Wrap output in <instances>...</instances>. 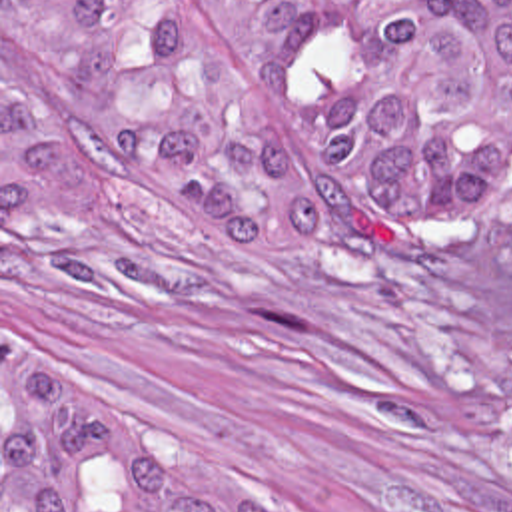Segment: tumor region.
Wrapping results in <instances>:
<instances>
[{"mask_svg": "<svg viewBox=\"0 0 512 512\" xmlns=\"http://www.w3.org/2000/svg\"><path fill=\"white\" fill-rule=\"evenodd\" d=\"M118 174L156 228L256 281L308 260V208L357 248L505 222L512 0H2V226L90 216ZM2 512L268 511L10 343Z\"/></svg>", "mask_w": 512, "mask_h": 512, "instance_id": "e687c5a6", "label": "tumor region"}]
</instances>
